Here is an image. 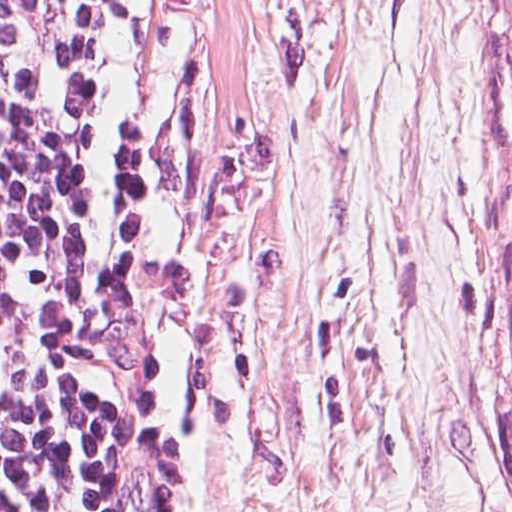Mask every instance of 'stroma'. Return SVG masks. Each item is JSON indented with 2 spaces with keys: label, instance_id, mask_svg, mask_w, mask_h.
<instances>
[{
  "label": "stroma",
  "instance_id": "obj_1",
  "mask_svg": "<svg viewBox=\"0 0 512 512\" xmlns=\"http://www.w3.org/2000/svg\"><path fill=\"white\" fill-rule=\"evenodd\" d=\"M495 0H58L50 207L169 204L145 512H512Z\"/></svg>",
  "mask_w": 512,
  "mask_h": 512
}]
</instances>
